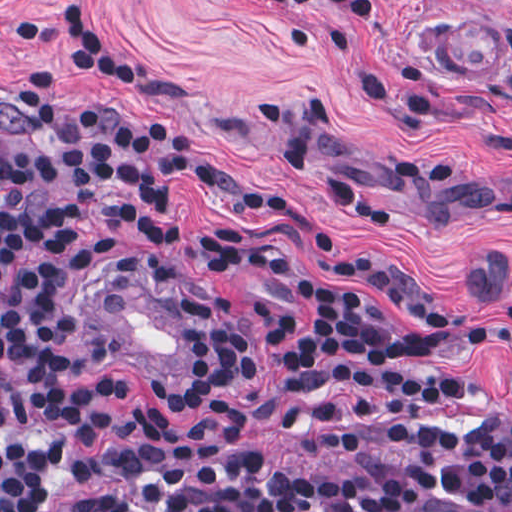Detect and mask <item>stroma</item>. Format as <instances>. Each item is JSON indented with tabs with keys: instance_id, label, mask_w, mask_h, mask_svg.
I'll return each instance as SVG.
<instances>
[{
	"instance_id": "35a3bbf8",
	"label": "stroma",
	"mask_w": 512,
	"mask_h": 512,
	"mask_svg": "<svg viewBox=\"0 0 512 512\" xmlns=\"http://www.w3.org/2000/svg\"><path fill=\"white\" fill-rule=\"evenodd\" d=\"M39 64L62 109L153 163L240 180L223 201L184 174L171 243L73 228L88 269L140 254L179 257L238 295L254 368L198 405L165 402L155 382L187 380V306L166 269H117L91 294L98 339L123 360L110 382L170 428L207 420L219 401L250 409L254 446L277 474L321 466L329 405L366 389H320L291 414L271 407L277 346L261 303L305 315L281 285L220 264L213 229L279 236L325 287L423 330L440 321L342 273L360 256L464 317L512 310V0H0V105ZM25 119L0 107V143L25 147ZM318 190H332L365 213ZM0 358L11 390L88 435L76 490L50 510L124 512L122 465L51 318L0 298ZM195 364V341H194ZM465 378L512 415V356L462 350L396 367ZM29 442L0 436V448Z\"/></svg>"
}]
</instances>
